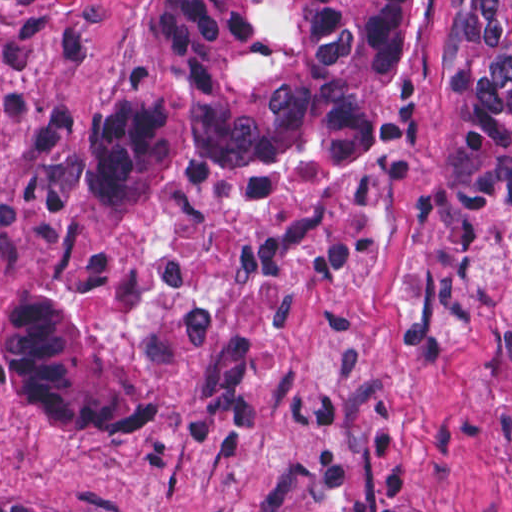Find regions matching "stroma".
I'll use <instances>...</instances> for the list:
<instances>
[{
    "label": "stroma",
    "mask_w": 512,
    "mask_h": 512,
    "mask_svg": "<svg viewBox=\"0 0 512 512\" xmlns=\"http://www.w3.org/2000/svg\"><path fill=\"white\" fill-rule=\"evenodd\" d=\"M143 0L0 3V330L99 258L89 173L147 77ZM462 0H411L398 90L415 159L448 155ZM116 344L153 433H66L0 367V489L73 512H512V229L444 262L416 166L315 201L238 182L166 192L124 227Z\"/></svg>",
    "instance_id": "35a3bbf8"
}]
</instances>
